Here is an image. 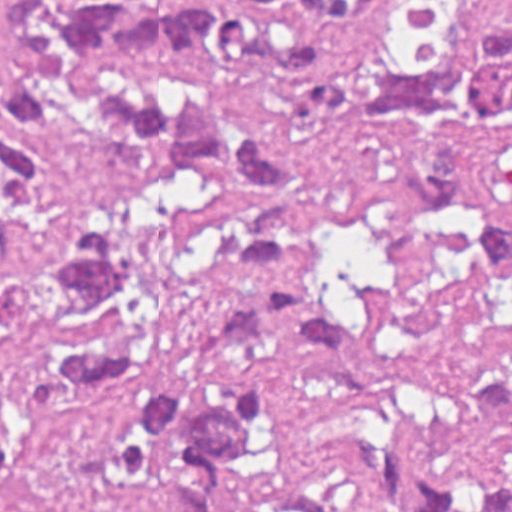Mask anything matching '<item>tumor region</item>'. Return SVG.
<instances>
[{
	"label": "tumor region",
	"instance_id": "tumor-region-1",
	"mask_svg": "<svg viewBox=\"0 0 512 512\" xmlns=\"http://www.w3.org/2000/svg\"><path fill=\"white\" fill-rule=\"evenodd\" d=\"M357 26L385 0H294ZM285 26L185 0H0V350L27 340L44 396L80 407L118 391L153 351V284L138 205L167 179L263 183L284 160L242 113L246 93L299 67ZM297 110L315 126L395 137L394 177L432 199L492 267L512 271V225L473 188L477 157L512 133V25L482 13L440 52L363 49L308 68ZM228 297L190 325L198 351L292 344L347 378L337 450L363 497L409 512H512L490 482L465 502L422 474L429 443L474 426L512 429V377L425 427L409 424L364 319L340 293L291 203L254 213ZM264 382L228 375L204 398L137 388L114 474L161 469L166 512H220L212 473L262 429ZM263 512H326L312 495Z\"/></svg>",
	"mask_w": 512,
	"mask_h": 512
}]
</instances>
